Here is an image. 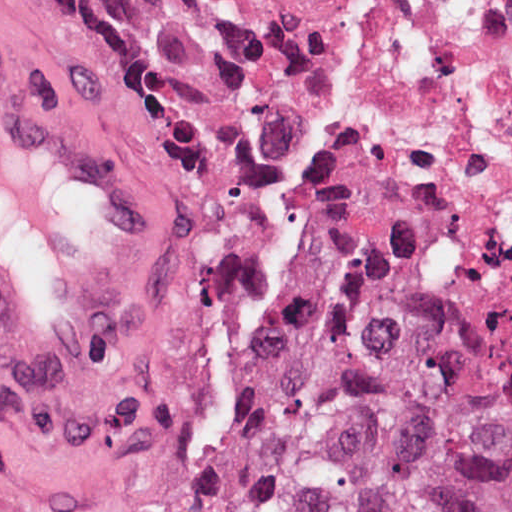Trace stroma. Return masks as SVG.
<instances>
[{"label":"stroma","mask_w":512,"mask_h":512,"mask_svg":"<svg viewBox=\"0 0 512 512\" xmlns=\"http://www.w3.org/2000/svg\"><path fill=\"white\" fill-rule=\"evenodd\" d=\"M161 3L167 46L100 70L0 0V60L149 170L105 355L74 376L0 380V512H190L226 331L313 259L246 149L197 0Z\"/></svg>","instance_id":"35a3bbf8"}]
</instances>
